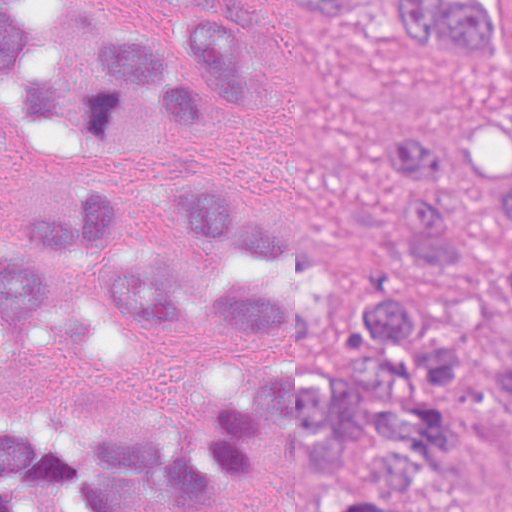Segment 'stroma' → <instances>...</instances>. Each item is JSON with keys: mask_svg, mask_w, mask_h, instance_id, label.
Listing matches in <instances>:
<instances>
[{"mask_svg": "<svg viewBox=\"0 0 512 512\" xmlns=\"http://www.w3.org/2000/svg\"><path fill=\"white\" fill-rule=\"evenodd\" d=\"M253 1L267 95L257 105L236 100L223 129L152 157L74 158L3 120L0 239L15 245L97 182L117 188L137 227L115 249L196 261L207 241L165 195L178 174L225 178L237 199L294 226L308 249L247 267L330 341L321 362L362 370L357 303L405 295L447 312L466 281L400 266L382 248L391 182L374 171V147L383 128L406 120L446 135L470 224L487 241L508 232L512 2L482 0L495 59L471 65L438 47L416 51L400 35L397 0H348L328 19L283 0ZM106 255L73 259L33 336L0 359V418L54 408L70 425L162 429L205 445L235 392L278 371L285 336L247 321H128L107 309L98 268ZM464 350L478 366H512L505 296L471 328ZM511 478L512 402L455 392L452 464L422 512H497ZM331 493L283 433H258V458L192 496L135 512H323ZM19 501L25 512H75L41 491Z\"/></svg>", "mask_w": 512, "mask_h": 512, "instance_id": "1", "label": "stroma"}]
</instances>
